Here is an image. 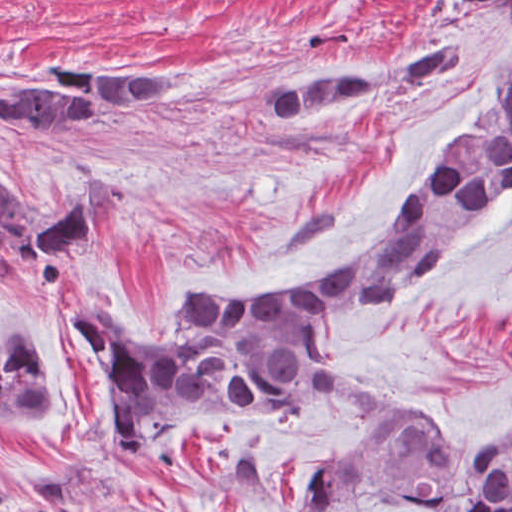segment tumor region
<instances>
[{
	"mask_svg": "<svg viewBox=\"0 0 512 512\" xmlns=\"http://www.w3.org/2000/svg\"><path fill=\"white\" fill-rule=\"evenodd\" d=\"M470 60L446 39L358 72L280 74L263 89L261 106L279 126L298 127L361 98L436 84L420 101L447 91ZM183 98L185 79L161 65L54 59L27 76H0V135L33 143L86 135L82 142L118 113ZM511 195L512 61L494 74L468 125L444 143L391 228L325 280L284 298L199 300L185 309L173 346L117 339L96 314L104 297L74 306L62 332L104 379L116 449L143 458L170 434L219 421L287 423L342 397L368 417L313 480L308 512L346 503L512 512V443L442 445L384 425L381 389L353 378L321 343L335 322L381 312L420 290ZM111 208V189L90 179L39 225L0 171V268L23 304L49 305L66 259ZM65 414V393L39 339L22 316L1 314L0 426ZM7 501L0 490V509Z\"/></svg>",
	"mask_w": 512,
	"mask_h": 512,
	"instance_id": "tumor-region-1",
	"label": "tumor region"
}]
</instances>
